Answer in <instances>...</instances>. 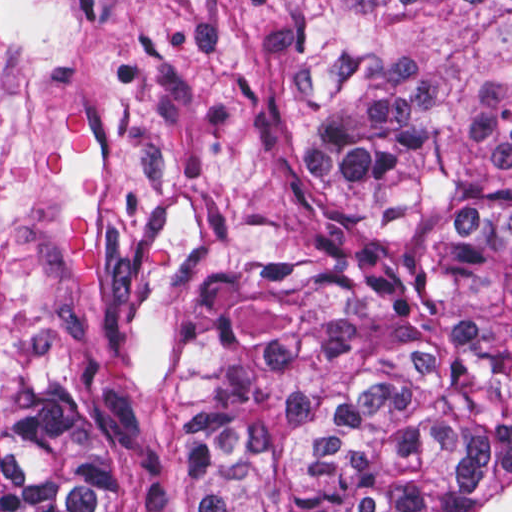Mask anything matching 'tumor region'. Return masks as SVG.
<instances>
[{"mask_svg": "<svg viewBox=\"0 0 512 512\" xmlns=\"http://www.w3.org/2000/svg\"><path fill=\"white\" fill-rule=\"evenodd\" d=\"M286 118L162 350L0 400V512H512V0H304Z\"/></svg>", "mask_w": 512, "mask_h": 512, "instance_id": "obj_1", "label": "tumor region"}]
</instances>
